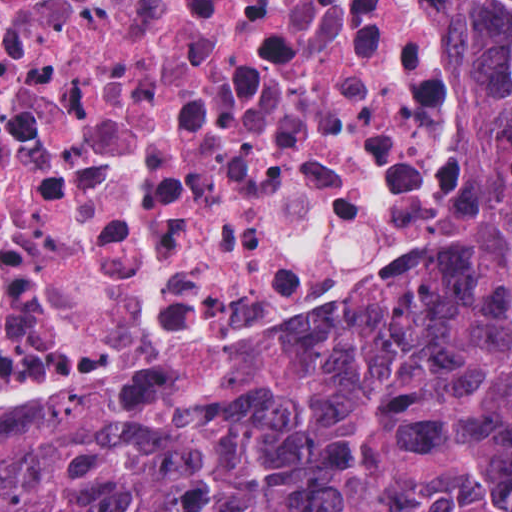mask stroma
<instances>
[{
    "label": "stroma",
    "mask_w": 512,
    "mask_h": 512,
    "mask_svg": "<svg viewBox=\"0 0 512 512\" xmlns=\"http://www.w3.org/2000/svg\"><path fill=\"white\" fill-rule=\"evenodd\" d=\"M467 20L477 53L490 75L495 130L496 67L485 34L468 17ZM496 142L503 154V191L497 223V249L481 269L455 284L435 294L411 297L399 304L512 280V140L496 132Z\"/></svg>",
    "instance_id": "stroma-1"
}]
</instances>
